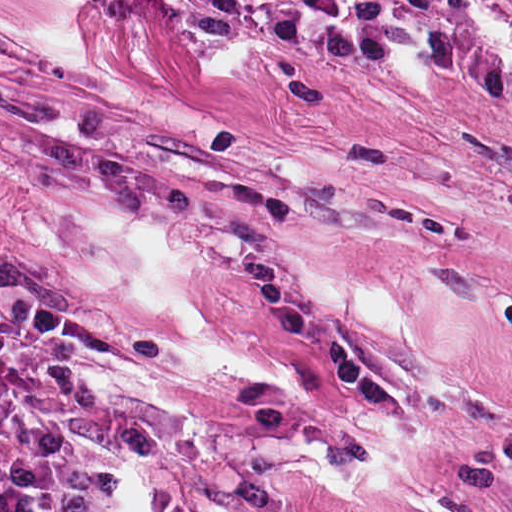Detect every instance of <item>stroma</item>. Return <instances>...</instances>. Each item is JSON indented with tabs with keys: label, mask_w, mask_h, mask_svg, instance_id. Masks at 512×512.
Segmentation results:
<instances>
[{
	"label": "stroma",
	"mask_w": 512,
	"mask_h": 512,
	"mask_svg": "<svg viewBox=\"0 0 512 512\" xmlns=\"http://www.w3.org/2000/svg\"><path fill=\"white\" fill-rule=\"evenodd\" d=\"M512 144V52L474 29H369L313 0H72Z\"/></svg>",
	"instance_id": "35a3bbf8"
}]
</instances>
